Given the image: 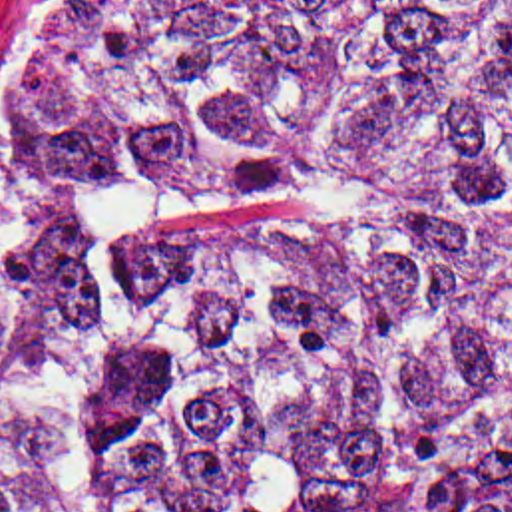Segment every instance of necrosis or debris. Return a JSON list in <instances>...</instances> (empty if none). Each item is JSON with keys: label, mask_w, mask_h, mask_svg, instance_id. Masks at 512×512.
Wrapping results in <instances>:
<instances>
[{"label": "necrosis or debris", "mask_w": 512, "mask_h": 512, "mask_svg": "<svg viewBox=\"0 0 512 512\" xmlns=\"http://www.w3.org/2000/svg\"><path fill=\"white\" fill-rule=\"evenodd\" d=\"M76 31H117L165 0H40Z\"/></svg>", "instance_id": "4bbe7bcc"}]
</instances>
